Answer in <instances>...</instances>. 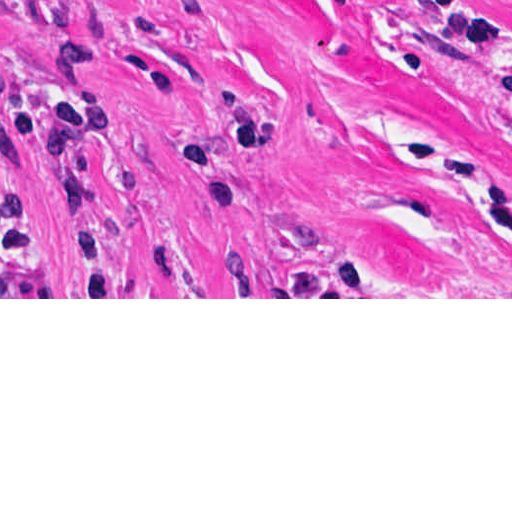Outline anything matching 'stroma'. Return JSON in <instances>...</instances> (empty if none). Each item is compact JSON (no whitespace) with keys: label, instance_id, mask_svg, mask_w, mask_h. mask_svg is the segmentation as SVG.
Instances as JSON below:
<instances>
[{"label":"stroma","instance_id":"1","mask_svg":"<svg viewBox=\"0 0 512 512\" xmlns=\"http://www.w3.org/2000/svg\"><path fill=\"white\" fill-rule=\"evenodd\" d=\"M0 299H512V0H0Z\"/></svg>","mask_w":512,"mask_h":512}]
</instances>
